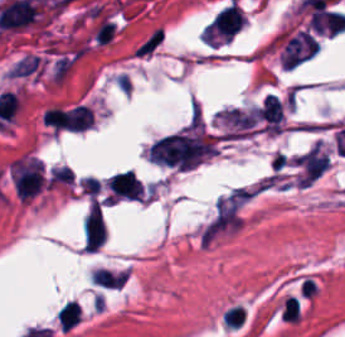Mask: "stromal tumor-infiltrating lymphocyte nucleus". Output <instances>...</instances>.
I'll list each match as a JSON object with an SVG mask.
<instances>
[{
  "label": "stromal tumor-infiltrating lymphocyte nucleus",
  "mask_w": 345,
  "mask_h": 337,
  "mask_svg": "<svg viewBox=\"0 0 345 337\" xmlns=\"http://www.w3.org/2000/svg\"><path fill=\"white\" fill-rule=\"evenodd\" d=\"M248 316L247 307L241 302H234L227 306L221 319L224 325L232 329H240L246 323Z\"/></svg>",
  "instance_id": "obj_3"
},
{
  "label": "stromal tumor-infiltrating lymphocyte nucleus",
  "mask_w": 345,
  "mask_h": 337,
  "mask_svg": "<svg viewBox=\"0 0 345 337\" xmlns=\"http://www.w3.org/2000/svg\"><path fill=\"white\" fill-rule=\"evenodd\" d=\"M107 191L109 200L114 202L139 199L143 194L138 178L128 169L110 177L107 183Z\"/></svg>",
  "instance_id": "obj_1"
},
{
  "label": "stromal tumor-infiltrating lymphocyte nucleus",
  "mask_w": 345,
  "mask_h": 337,
  "mask_svg": "<svg viewBox=\"0 0 345 337\" xmlns=\"http://www.w3.org/2000/svg\"><path fill=\"white\" fill-rule=\"evenodd\" d=\"M84 315L82 304L75 298H67L56 311V322L61 329L74 330Z\"/></svg>",
  "instance_id": "obj_2"
}]
</instances>
